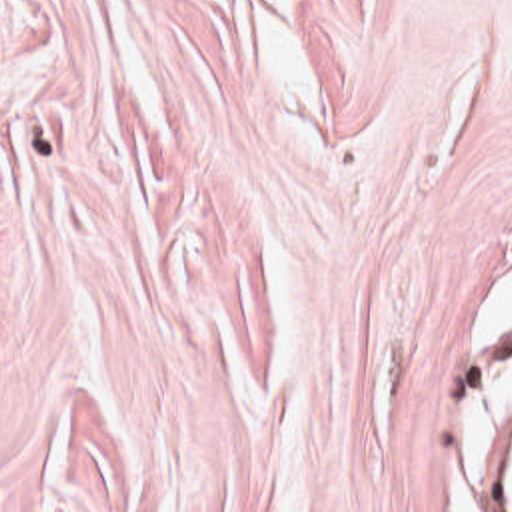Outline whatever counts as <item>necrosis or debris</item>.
I'll use <instances>...</instances> for the list:
<instances>
[{
    "mask_svg": "<svg viewBox=\"0 0 512 512\" xmlns=\"http://www.w3.org/2000/svg\"><path fill=\"white\" fill-rule=\"evenodd\" d=\"M486 355L500 357L512 365V347ZM486 463L490 467L498 511L512 512V413L504 415L486 433Z\"/></svg>",
    "mask_w": 512,
    "mask_h": 512,
    "instance_id": "1",
    "label": "necrosis or debris"
}]
</instances>
